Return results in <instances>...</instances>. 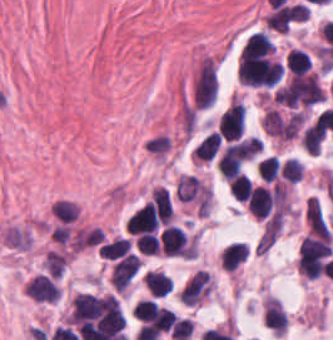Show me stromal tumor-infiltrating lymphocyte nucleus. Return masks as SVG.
<instances>
[{"label": "stromal tumor-infiltrating lymphocyte nucleus", "instance_id": "obj_10", "mask_svg": "<svg viewBox=\"0 0 333 340\" xmlns=\"http://www.w3.org/2000/svg\"><path fill=\"white\" fill-rule=\"evenodd\" d=\"M228 188L234 198L245 201L250 193V182L244 173H236L228 181Z\"/></svg>", "mask_w": 333, "mask_h": 340}, {"label": "stromal tumor-infiltrating lymphocyte nucleus", "instance_id": "obj_15", "mask_svg": "<svg viewBox=\"0 0 333 340\" xmlns=\"http://www.w3.org/2000/svg\"><path fill=\"white\" fill-rule=\"evenodd\" d=\"M156 302L149 298H141L133 308V318L140 322H152L155 316Z\"/></svg>", "mask_w": 333, "mask_h": 340}, {"label": "stromal tumor-infiltrating lymphocyte nucleus", "instance_id": "obj_9", "mask_svg": "<svg viewBox=\"0 0 333 340\" xmlns=\"http://www.w3.org/2000/svg\"><path fill=\"white\" fill-rule=\"evenodd\" d=\"M218 141L219 136L217 132L211 131L205 135L194 149L193 158L199 160H210L215 153Z\"/></svg>", "mask_w": 333, "mask_h": 340}, {"label": "stromal tumor-infiltrating lymphocyte nucleus", "instance_id": "obj_1", "mask_svg": "<svg viewBox=\"0 0 333 340\" xmlns=\"http://www.w3.org/2000/svg\"><path fill=\"white\" fill-rule=\"evenodd\" d=\"M25 293L29 299L37 302L55 303L59 298L60 285L56 277L40 272L26 281Z\"/></svg>", "mask_w": 333, "mask_h": 340}, {"label": "stromal tumor-infiltrating lymphocyte nucleus", "instance_id": "obj_17", "mask_svg": "<svg viewBox=\"0 0 333 340\" xmlns=\"http://www.w3.org/2000/svg\"><path fill=\"white\" fill-rule=\"evenodd\" d=\"M159 240L152 233H139L135 249L141 254H157Z\"/></svg>", "mask_w": 333, "mask_h": 340}, {"label": "stromal tumor-infiltrating lymphocyte nucleus", "instance_id": "obj_12", "mask_svg": "<svg viewBox=\"0 0 333 340\" xmlns=\"http://www.w3.org/2000/svg\"><path fill=\"white\" fill-rule=\"evenodd\" d=\"M129 242L120 238H114L99 246V257L104 259H116L127 253Z\"/></svg>", "mask_w": 333, "mask_h": 340}, {"label": "stromal tumor-infiltrating lymphocyte nucleus", "instance_id": "obj_14", "mask_svg": "<svg viewBox=\"0 0 333 340\" xmlns=\"http://www.w3.org/2000/svg\"><path fill=\"white\" fill-rule=\"evenodd\" d=\"M303 163L295 157H288L279 169V176L288 183H295L301 176Z\"/></svg>", "mask_w": 333, "mask_h": 340}, {"label": "stromal tumor-infiltrating lymphocyte nucleus", "instance_id": "obj_11", "mask_svg": "<svg viewBox=\"0 0 333 340\" xmlns=\"http://www.w3.org/2000/svg\"><path fill=\"white\" fill-rule=\"evenodd\" d=\"M42 263L46 271L52 276L60 277L66 263L65 253L55 250H47L44 254Z\"/></svg>", "mask_w": 333, "mask_h": 340}, {"label": "stromal tumor-infiltrating lymphocyte nucleus", "instance_id": "obj_13", "mask_svg": "<svg viewBox=\"0 0 333 340\" xmlns=\"http://www.w3.org/2000/svg\"><path fill=\"white\" fill-rule=\"evenodd\" d=\"M279 170L278 161L274 156H267L259 159L255 163V171L258 178L271 181L275 178Z\"/></svg>", "mask_w": 333, "mask_h": 340}, {"label": "stromal tumor-infiltrating lymphocyte nucleus", "instance_id": "obj_3", "mask_svg": "<svg viewBox=\"0 0 333 340\" xmlns=\"http://www.w3.org/2000/svg\"><path fill=\"white\" fill-rule=\"evenodd\" d=\"M211 289L209 272L197 271L180 291V301L196 305L204 299Z\"/></svg>", "mask_w": 333, "mask_h": 340}, {"label": "stromal tumor-infiltrating lymphocyte nucleus", "instance_id": "obj_6", "mask_svg": "<svg viewBox=\"0 0 333 340\" xmlns=\"http://www.w3.org/2000/svg\"><path fill=\"white\" fill-rule=\"evenodd\" d=\"M248 246L245 242H231L221 250L220 263L226 271H232L245 261Z\"/></svg>", "mask_w": 333, "mask_h": 340}, {"label": "stromal tumor-infiltrating lymphocyte nucleus", "instance_id": "obj_7", "mask_svg": "<svg viewBox=\"0 0 333 340\" xmlns=\"http://www.w3.org/2000/svg\"><path fill=\"white\" fill-rule=\"evenodd\" d=\"M144 286L153 297H162L171 291L170 279L165 273L148 271L143 277Z\"/></svg>", "mask_w": 333, "mask_h": 340}, {"label": "stromal tumor-infiltrating lymphocyte nucleus", "instance_id": "obj_5", "mask_svg": "<svg viewBox=\"0 0 333 340\" xmlns=\"http://www.w3.org/2000/svg\"><path fill=\"white\" fill-rule=\"evenodd\" d=\"M274 51L270 39L262 32L250 33L240 48V60H251Z\"/></svg>", "mask_w": 333, "mask_h": 340}, {"label": "stromal tumor-infiltrating lymphocyte nucleus", "instance_id": "obj_4", "mask_svg": "<svg viewBox=\"0 0 333 340\" xmlns=\"http://www.w3.org/2000/svg\"><path fill=\"white\" fill-rule=\"evenodd\" d=\"M139 264L140 260L134 253L128 252L120 257L111 270V284L120 292L124 290L135 275Z\"/></svg>", "mask_w": 333, "mask_h": 340}, {"label": "stromal tumor-infiltrating lymphocyte nucleus", "instance_id": "obj_2", "mask_svg": "<svg viewBox=\"0 0 333 340\" xmlns=\"http://www.w3.org/2000/svg\"><path fill=\"white\" fill-rule=\"evenodd\" d=\"M244 126V113L241 104L230 99L218 123L219 134L224 139H237Z\"/></svg>", "mask_w": 333, "mask_h": 340}, {"label": "stromal tumor-infiltrating lymphocyte nucleus", "instance_id": "obj_8", "mask_svg": "<svg viewBox=\"0 0 333 340\" xmlns=\"http://www.w3.org/2000/svg\"><path fill=\"white\" fill-rule=\"evenodd\" d=\"M309 56L299 48H292L285 59V68L292 74L303 75L308 70Z\"/></svg>", "mask_w": 333, "mask_h": 340}, {"label": "stromal tumor-infiltrating lymphocyte nucleus", "instance_id": "obj_16", "mask_svg": "<svg viewBox=\"0 0 333 340\" xmlns=\"http://www.w3.org/2000/svg\"><path fill=\"white\" fill-rule=\"evenodd\" d=\"M146 150L156 157H164L169 152V136L156 134L146 139Z\"/></svg>", "mask_w": 333, "mask_h": 340}, {"label": "stromal tumor-infiltrating lymphocyte nucleus", "instance_id": "obj_18", "mask_svg": "<svg viewBox=\"0 0 333 340\" xmlns=\"http://www.w3.org/2000/svg\"><path fill=\"white\" fill-rule=\"evenodd\" d=\"M193 328L194 327L191 321L184 319L182 317L178 318L177 320L174 321L173 325L169 330V337L171 340H175L178 338L189 336Z\"/></svg>", "mask_w": 333, "mask_h": 340}]
</instances>
